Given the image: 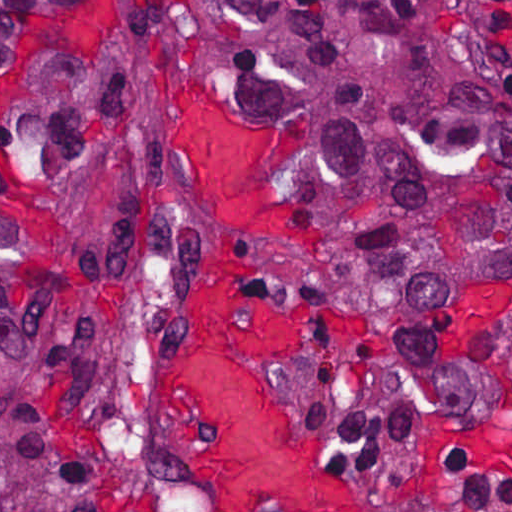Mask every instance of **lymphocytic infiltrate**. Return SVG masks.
I'll list each match as a JSON object with an SVG mask.
<instances>
[{
	"label": "lymphocytic infiltrate",
	"mask_w": 512,
	"mask_h": 512,
	"mask_svg": "<svg viewBox=\"0 0 512 512\" xmlns=\"http://www.w3.org/2000/svg\"><path fill=\"white\" fill-rule=\"evenodd\" d=\"M443 462L454 491L428 512H512V475L485 473L464 452H449Z\"/></svg>",
	"instance_id": "lymphocytic-infiltrate-1"
}]
</instances>
